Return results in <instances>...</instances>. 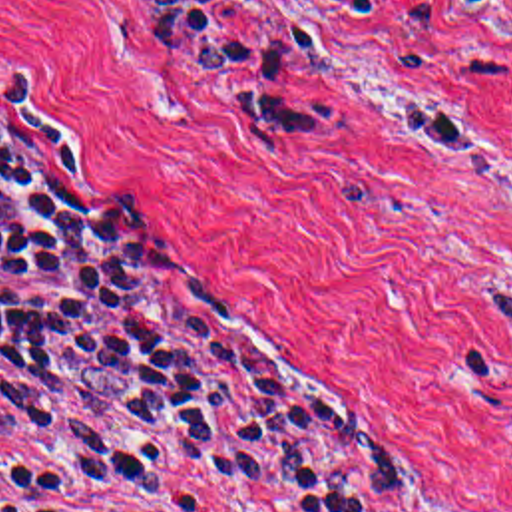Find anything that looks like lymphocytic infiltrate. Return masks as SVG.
I'll list each match as a JSON object with an SVG mask.
<instances>
[{"label": "lymphocytic infiltrate", "instance_id": "lymphocytic-infiltrate-1", "mask_svg": "<svg viewBox=\"0 0 512 512\" xmlns=\"http://www.w3.org/2000/svg\"><path fill=\"white\" fill-rule=\"evenodd\" d=\"M394 27L396 0H330ZM151 53L206 97L324 149L346 113L296 83L276 45L218 0H125ZM286 25L300 55L334 35ZM0 413L53 437L57 461L0 457V512H161L187 481L236 483L272 512H382L410 495V457L310 395L206 346L159 284L131 212L57 145L0 119Z\"/></svg>", "mask_w": 512, "mask_h": 512}]
</instances>
